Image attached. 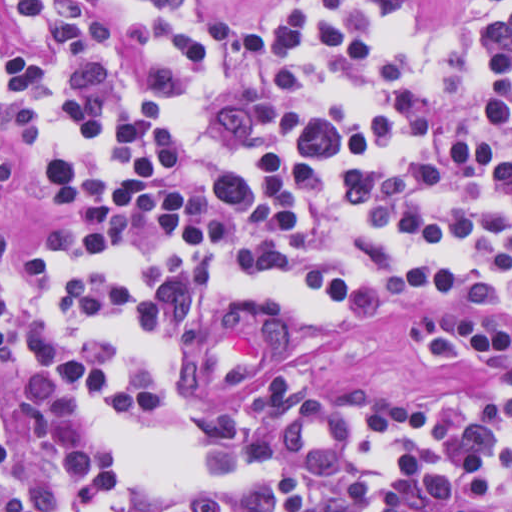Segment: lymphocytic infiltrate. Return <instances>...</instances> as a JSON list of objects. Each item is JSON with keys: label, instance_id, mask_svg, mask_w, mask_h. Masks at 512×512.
Wrapping results in <instances>:
<instances>
[{"label": "lymphocytic infiltrate", "instance_id": "1", "mask_svg": "<svg viewBox=\"0 0 512 512\" xmlns=\"http://www.w3.org/2000/svg\"><path fill=\"white\" fill-rule=\"evenodd\" d=\"M511 121L512 1H1V512H512ZM424 299L473 389L213 403Z\"/></svg>", "mask_w": 512, "mask_h": 512}]
</instances>
